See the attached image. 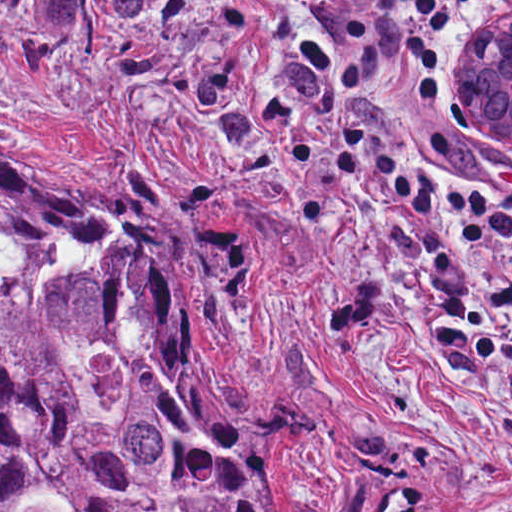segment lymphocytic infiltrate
Returning a JSON list of instances; mask_svg holds the SVG:
<instances>
[{"label": "lymphocytic infiltrate", "instance_id": "f902f5d3", "mask_svg": "<svg viewBox=\"0 0 512 512\" xmlns=\"http://www.w3.org/2000/svg\"><path fill=\"white\" fill-rule=\"evenodd\" d=\"M290 48L323 91L343 171L375 179L397 207L486 236L512 279V193L420 173L384 94L432 103L448 77L460 14L474 0H269Z\"/></svg>", "mask_w": 512, "mask_h": 512}]
</instances>
